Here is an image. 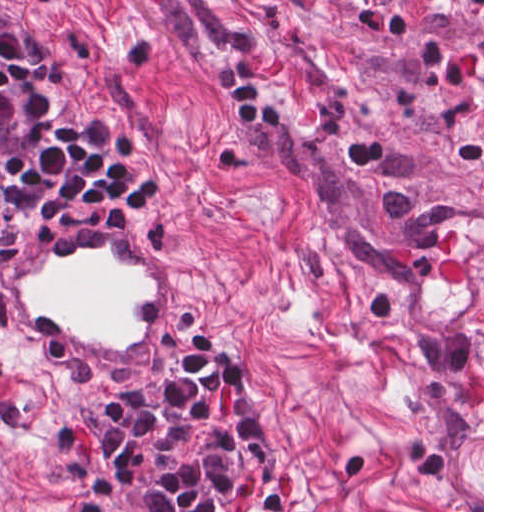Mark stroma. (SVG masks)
I'll use <instances>...</instances> for the list:
<instances>
[{
	"instance_id": "stroma-1",
	"label": "stroma",
	"mask_w": 512,
	"mask_h": 512,
	"mask_svg": "<svg viewBox=\"0 0 512 512\" xmlns=\"http://www.w3.org/2000/svg\"><path fill=\"white\" fill-rule=\"evenodd\" d=\"M0 512H123L0 402Z\"/></svg>"
}]
</instances>
